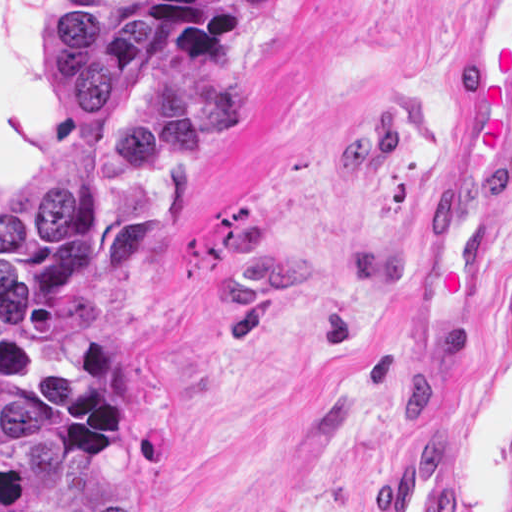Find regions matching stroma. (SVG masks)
Returning a JSON list of instances; mask_svg holds the SVG:
<instances>
[{
  "mask_svg": "<svg viewBox=\"0 0 512 512\" xmlns=\"http://www.w3.org/2000/svg\"><path fill=\"white\" fill-rule=\"evenodd\" d=\"M139 74L239 109L216 160L149 175L153 269L94 333L114 351L142 453L135 512H377L432 430L456 512L512 502V189L489 319L446 379L391 375L453 141L466 0H142ZM53 0H0V201L73 147Z\"/></svg>",
  "mask_w": 512,
  "mask_h": 512,
  "instance_id": "obj_1",
  "label": "stroma"
}]
</instances>
